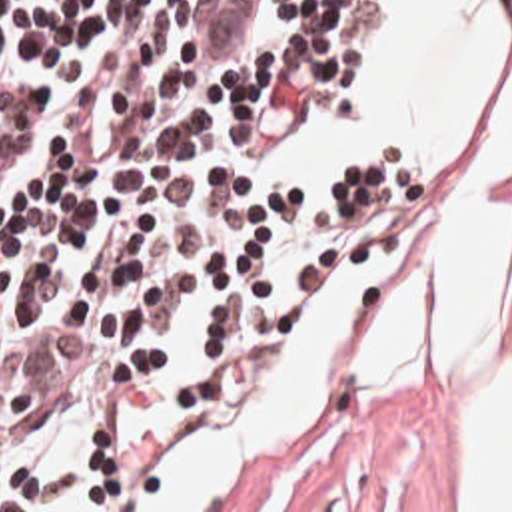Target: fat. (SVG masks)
<instances>
[{"mask_svg": "<svg viewBox=\"0 0 512 512\" xmlns=\"http://www.w3.org/2000/svg\"><path fill=\"white\" fill-rule=\"evenodd\" d=\"M416 237L374 333L392 393H460V512H512V0L486 95L446 149H402Z\"/></svg>", "mask_w": 512, "mask_h": 512, "instance_id": "fat-1", "label": "fat"}]
</instances>
